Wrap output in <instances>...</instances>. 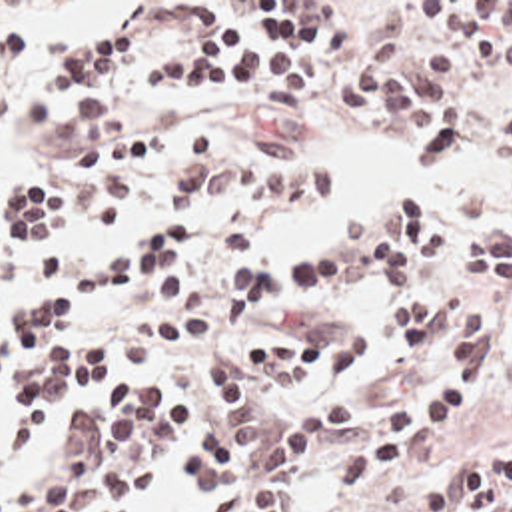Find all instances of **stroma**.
<instances>
[{"label": "stroma", "instance_id": "35a3bbf8", "mask_svg": "<svg viewBox=\"0 0 512 512\" xmlns=\"http://www.w3.org/2000/svg\"><path fill=\"white\" fill-rule=\"evenodd\" d=\"M195 2H225L253 24V2H325L323 10L347 26V46L341 52L317 56L315 80L289 118H259L247 94L195 98L177 84L145 98L137 80L145 70L189 58L199 50L195 30L183 24L181 12ZM411 2H512V0H0V28L12 22L58 26L82 36L105 34L121 24L143 28L147 56L139 68L103 76L102 98L141 130L181 138L203 132L221 140L231 158L243 156L251 138L297 142L309 158L333 170V196L317 204H275L263 212V226L243 248H219L217 220L221 210L199 214L169 212L163 190L169 180L145 176L135 182L129 210L121 224L107 228L78 216L66 198V178L72 158V138L56 124L36 126L24 110L26 94L52 66L58 46L50 44L18 62H0V186L16 178H50L64 190V208L42 236L56 238L70 254V272L90 268L115 254L141 228L179 220L187 224V248L161 266L149 280L111 292H70L60 288L30 290L0 278V312H16L56 292L74 312L78 347H94L105 327L125 329L153 313L197 308L209 315V333L175 349L167 363L147 371H123L103 387L66 401L38 431L22 435L16 429V405L0 433L4 479L0 491L20 485L48 469L68 451L72 419L90 407L103 405L117 389L131 383L157 385L167 395V409L181 415L187 439L195 431L227 425V411L203 373V353L211 349L249 351L279 333H301L325 317H341L361 327L369 337L361 369L337 383H289L271 391L263 415H277L293 405L347 397L363 391L395 365L397 341L387 329V286L375 268H363L355 246L339 232L349 220L381 204L391 192L411 186L421 190L439 210L451 240L449 248L411 280L419 296H445L463 274L469 254V234L511 208L512 166L483 160L467 152L449 164H423L417 154V132L407 114L351 108L341 94L347 72L369 46L399 30L423 44H449L461 52L459 40L421 28L413 22ZM323 250H343L347 280L313 290H271L261 319L253 325H219L217 306L227 298L219 292V270L235 258H257L291 268ZM483 313L485 367L465 371L475 383V401L451 419H431L417 427L403 459L391 469L357 483L349 495H333L323 481V463L379 441L391 419L387 411L403 399H419L435 389L445 371L403 377L375 397L345 433L325 451L301 463L285 481L281 512H419L411 505L415 479L449 467L485 447H512V361L499 351V335L512 312V292L477 288L473 294ZM183 451L153 487L143 489L133 509L141 512H209L189 491L183 475Z\"/></svg>", "mask_w": 512, "mask_h": 512}]
</instances>
